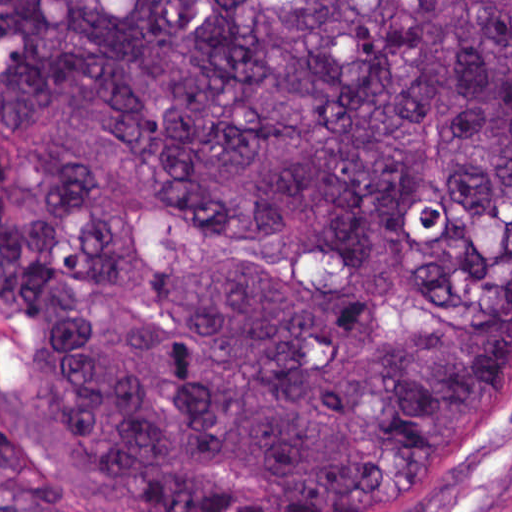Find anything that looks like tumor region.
I'll return each mask as SVG.
<instances>
[{
    "mask_svg": "<svg viewBox=\"0 0 512 512\" xmlns=\"http://www.w3.org/2000/svg\"><path fill=\"white\" fill-rule=\"evenodd\" d=\"M18 414L134 512H402L512 344V0H0ZM0 512H123L0 418Z\"/></svg>",
    "mask_w": 512,
    "mask_h": 512,
    "instance_id": "obj_1",
    "label": "tumor region"
}]
</instances>
